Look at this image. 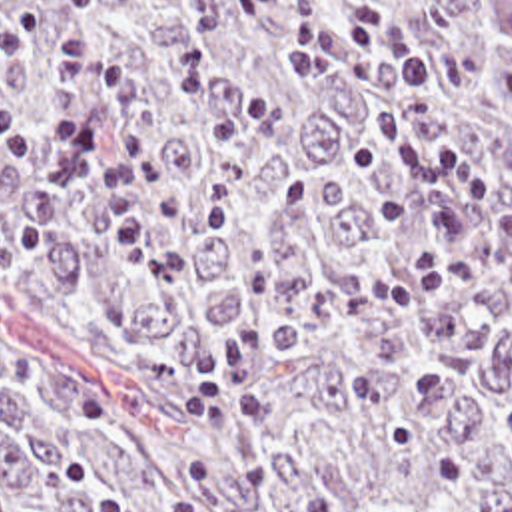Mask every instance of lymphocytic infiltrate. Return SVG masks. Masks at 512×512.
<instances>
[{
    "instance_id": "1",
    "label": "lymphocytic infiltrate",
    "mask_w": 512,
    "mask_h": 512,
    "mask_svg": "<svg viewBox=\"0 0 512 512\" xmlns=\"http://www.w3.org/2000/svg\"><path fill=\"white\" fill-rule=\"evenodd\" d=\"M366 53L364 75L386 87L388 101L370 117L378 151L398 161L402 183H436L422 195L434 227L468 237L464 245H428L416 255L418 291L434 295L470 281L488 265L512 295V199L472 157L432 139L430 113L438 105V65L424 43L398 19L372 15L326 27L314 55L336 57L340 45ZM49 127L35 129L23 105L0 99V149L9 169L35 197L56 193V165L82 123L86 87L114 97L110 149L86 189L92 233L104 259L126 273H154L162 263V221L140 171L150 153L142 109L146 77L116 53L100 47L84 27L54 41Z\"/></svg>"
}]
</instances>
